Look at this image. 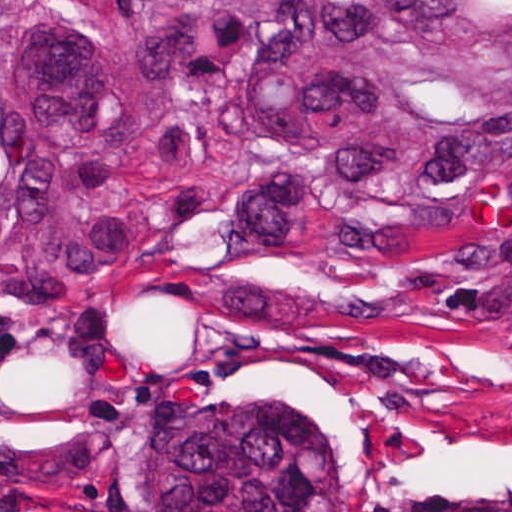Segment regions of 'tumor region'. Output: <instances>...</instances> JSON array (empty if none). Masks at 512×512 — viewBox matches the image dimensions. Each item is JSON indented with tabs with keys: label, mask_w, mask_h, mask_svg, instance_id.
Masks as SVG:
<instances>
[{
	"label": "tumor region",
	"mask_w": 512,
	"mask_h": 512,
	"mask_svg": "<svg viewBox=\"0 0 512 512\" xmlns=\"http://www.w3.org/2000/svg\"><path fill=\"white\" fill-rule=\"evenodd\" d=\"M505 210L461 331L512 340V0H0V320L95 298L221 218L371 255ZM152 512H341L309 418L200 400Z\"/></svg>",
	"instance_id": "e687c5a6"
}]
</instances>
